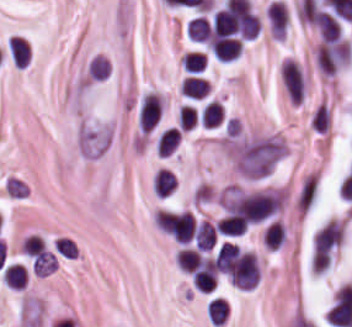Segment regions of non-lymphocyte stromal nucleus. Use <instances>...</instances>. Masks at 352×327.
<instances>
[{
    "label": "non-lymphocyte stromal nucleus",
    "mask_w": 352,
    "mask_h": 327,
    "mask_svg": "<svg viewBox=\"0 0 352 327\" xmlns=\"http://www.w3.org/2000/svg\"><path fill=\"white\" fill-rule=\"evenodd\" d=\"M321 174L308 170L301 178L292 202L297 211L308 213L312 210L320 192Z\"/></svg>",
    "instance_id": "non-lymphocyte-stromal-nucleus-1"
}]
</instances>
